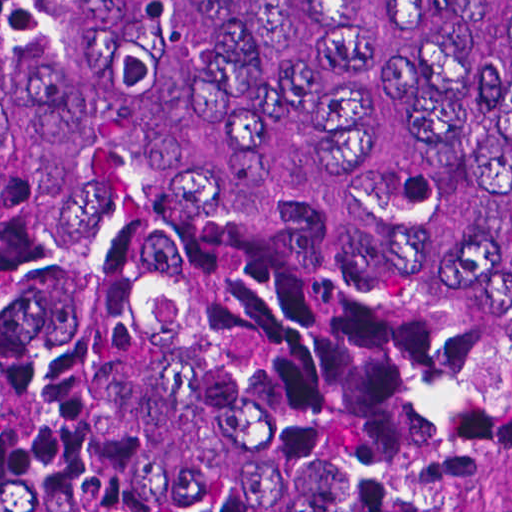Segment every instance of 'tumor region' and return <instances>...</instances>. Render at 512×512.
I'll return each instance as SVG.
<instances>
[{"label":"tumor region","mask_w":512,"mask_h":512,"mask_svg":"<svg viewBox=\"0 0 512 512\" xmlns=\"http://www.w3.org/2000/svg\"><path fill=\"white\" fill-rule=\"evenodd\" d=\"M512 494V0H0V512Z\"/></svg>","instance_id":"1"}]
</instances>
